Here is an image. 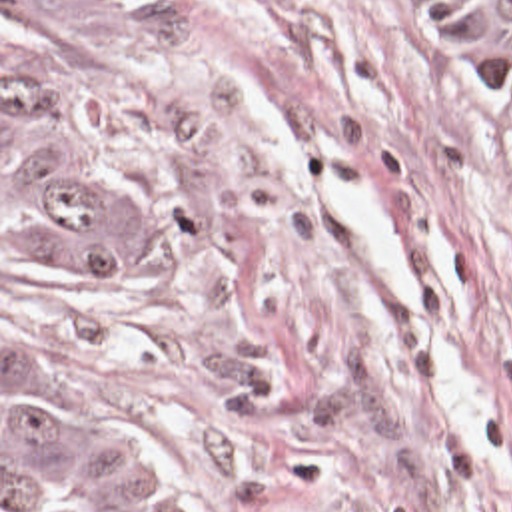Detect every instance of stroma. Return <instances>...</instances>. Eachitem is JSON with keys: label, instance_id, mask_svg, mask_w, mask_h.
Segmentation results:
<instances>
[{"label": "stroma", "instance_id": "35a3bbf8", "mask_svg": "<svg viewBox=\"0 0 512 512\" xmlns=\"http://www.w3.org/2000/svg\"><path fill=\"white\" fill-rule=\"evenodd\" d=\"M116 287L2 329L166 430L208 512H512V101L453 0H120Z\"/></svg>", "mask_w": 512, "mask_h": 512}]
</instances>
